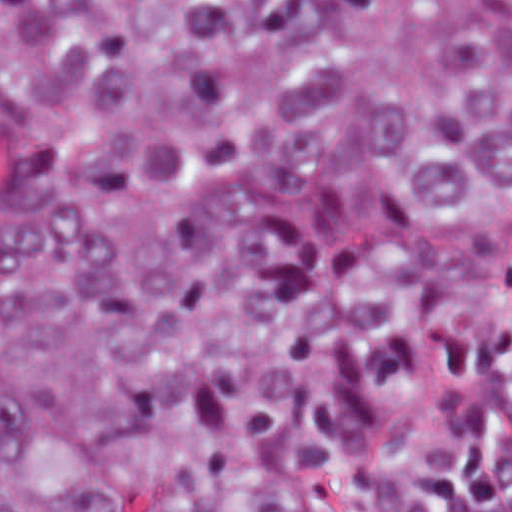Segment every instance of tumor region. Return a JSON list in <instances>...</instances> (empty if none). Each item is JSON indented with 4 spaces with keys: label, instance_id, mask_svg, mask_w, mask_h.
I'll return each mask as SVG.
<instances>
[{
    "label": "tumor region",
    "instance_id": "1",
    "mask_svg": "<svg viewBox=\"0 0 512 512\" xmlns=\"http://www.w3.org/2000/svg\"><path fill=\"white\" fill-rule=\"evenodd\" d=\"M512 274V1H0V512H373Z\"/></svg>",
    "mask_w": 512,
    "mask_h": 512
}]
</instances>
